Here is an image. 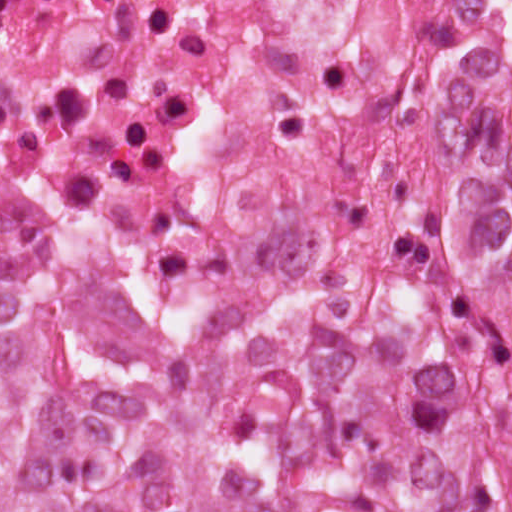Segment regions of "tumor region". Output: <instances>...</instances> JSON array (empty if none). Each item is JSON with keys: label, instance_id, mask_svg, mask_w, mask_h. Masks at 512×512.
Returning a JSON list of instances; mask_svg holds the SVG:
<instances>
[{"label": "tumor region", "instance_id": "e687c5a6", "mask_svg": "<svg viewBox=\"0 0 512 512\" xmlns=\"http://www.w3.org/2000/svg\"><path fill=\"white\" fill-rule=\"evenodd\" d=\"M0 512H512V194L419 261L94 214L0 275Z\"/></svg>", "mask_w": 512, "mask_h": 512}]
</instances>
